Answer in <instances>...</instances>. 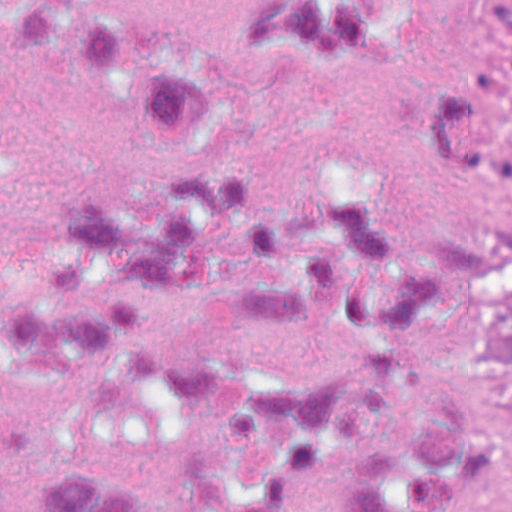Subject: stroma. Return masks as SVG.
<instances>
[{"mask_svg": "<svg viewBox=\"0 0 512 512\" xmlns=\"http://www.w3.org/2000/svg\"><path fill=\"white\" fill-rule=\"evenodd\" d=\"M495 0H452V73L469 51L471 18L488 2ZM512 219V212L485 208L465 201V231L499 220ZM489 482L499 512H512V429L499 450Z\"/></svg>", "mask_w": 512, "mask_h": 512, "instance_id": "35a3bbf8", "label": "stroma"}]
</instances>
